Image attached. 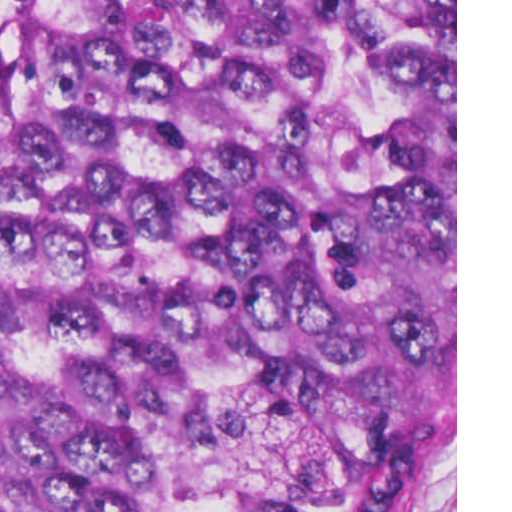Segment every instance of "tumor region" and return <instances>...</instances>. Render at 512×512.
<instances>
[{
	"instance_id": "obj_1",
	"label": "tumor region",
	"mask_w": 512,
	"mask_h": 512,
	"mask_svg": "<svg viewBox=\"0 0 512 512\" xmlns=\"http://www.w3.org/2000/svg\"><path fill=\"white\" fill-rule=\"evenodd\" d=\"M452 461L455 0H0V512Z\"/></svg>"
}]
</instances>
